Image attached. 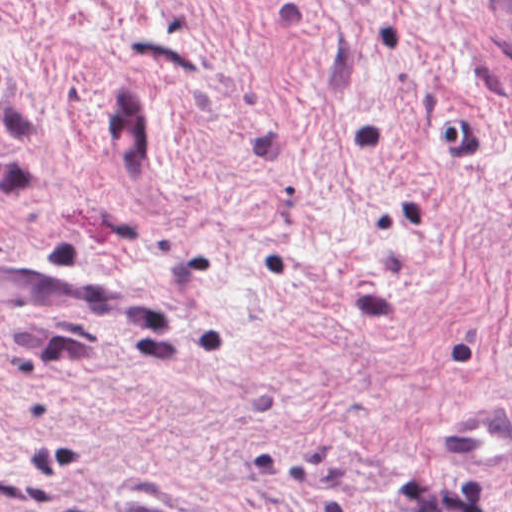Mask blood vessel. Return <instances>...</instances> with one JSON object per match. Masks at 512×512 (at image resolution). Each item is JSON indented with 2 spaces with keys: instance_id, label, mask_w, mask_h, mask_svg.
Wrapping results in <instances>:
<instances>
[{
  "instance_id": "1",
  "label": "blood vessel",
  "mask_w": 512,
  "mask_h": 512,
  "mask_svg": "<svg viewBox=\"0 0 512 512\" xmlns=\"http://www.w3.org/2000/svg\"><path fill=\"white\" fill-rule=\"evenodd\" d=\"M63 293H125L100 274H43L0 264V296ZM507 409L469 403L454 411L443 437L448 452L470 459L512 455V423Z\"/></svg>"
}]
</instances>
